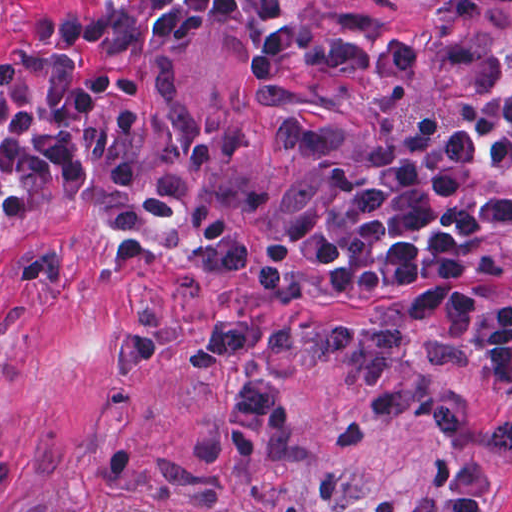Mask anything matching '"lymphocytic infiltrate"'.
Here are the masks:
<instances>
[{"label":"lymphocytic infiltrate","mask_w":512,"mask_h":512,"mask_svg":"<svg viewBox=\"0 0 512 512\" xmlns=\"http://www.w3.org/2000/svg\"><path fill=\"white\" fill-rule=\"evenodd\" d=\"M210 31L257 46V89L280 86L320 25L260 0H90L0 53L4 204H59L101 234L159 195L130 118L94 79L179 63ZM458 112L352 161L253 240L205 246V280L283 301L371 289L400 298L512 263V59L469 45L446 63Z\"/></svg>","instance_id":"obj_1"}]
</instances>
